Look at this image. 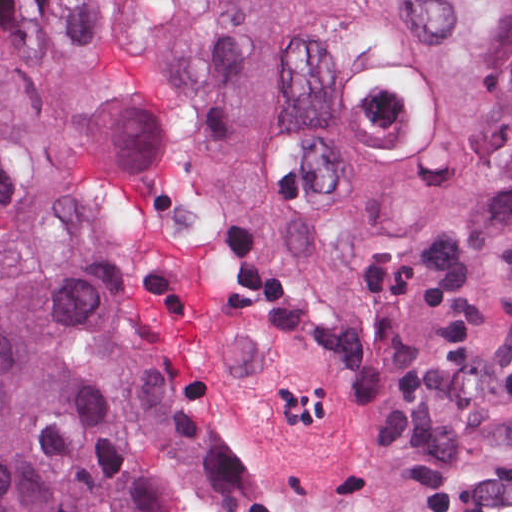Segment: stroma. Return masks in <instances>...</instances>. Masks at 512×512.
<instances>
[{"instance_id": "obj_1", "label": "stroma", "mask_w": 512, "mask_h": 512, "mask_svg": "<svg viewBox=\"0 0 512 512\" xmlns=\"http://www.w3.org/2000/svg\"><path fill=\"white\" fill-rule=\"evenodd\" d=\"M0 1H27L51 34L47 0ZM112 241L121 258L113 237ZM187 385L207 452V496L200 512H217L228 475V447L207 407ZM401 512H512V470H484L431 483L407 502Z\"/></svg>"}]
</instances>
